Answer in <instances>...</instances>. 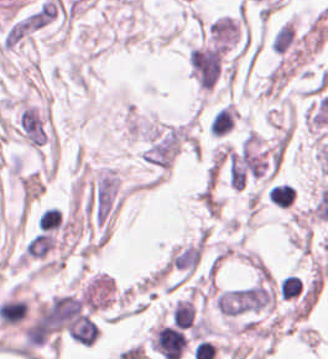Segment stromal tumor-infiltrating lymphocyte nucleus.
Listing matches in <instances>:
<instances>
[{"mask_svg": "<svg viewBox=\"0 0 328 359\" xmlns=\"http://www.w3.org/2000/svg\"><path fill=\"white\" fill-rule=\"evenodd\" d=\"M236 111L233 105H226L221 109L215 111L211 121V131L213 135H222L225 132L232 129L235 118H236Z\"/></svg>", "mask_w": 328, "mask_h": 359, "instance_id": "stromal-tumor-infiltrating-lymphocyte-nucleus-1", "label": "stromal tumor-infiltrating lymphocyte nucleus"}]
</instances>
